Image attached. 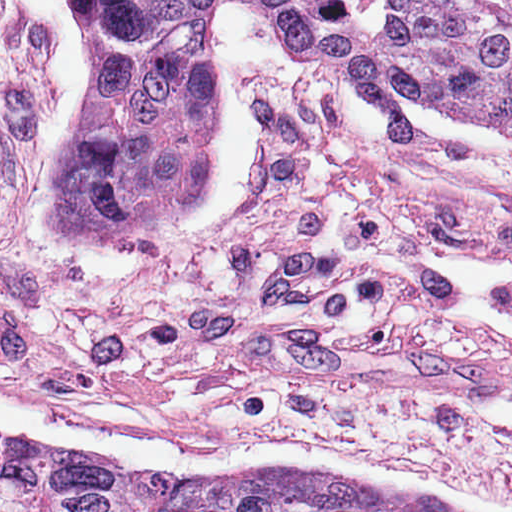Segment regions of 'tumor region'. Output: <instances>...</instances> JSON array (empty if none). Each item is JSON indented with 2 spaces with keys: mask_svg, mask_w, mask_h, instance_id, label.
Wrapping results in <instances>:
<instances>
[{
  "mask_svg": "<svg viewBox=\"0 0 512 512\" xmlns=\"http://www.w3.org/2000/svg\"><path fill=\"white\" fill-rule=\"evenodd\" d=\"M83 1L90 97L49 188L72 240L152 244L211 186L221 87L203 29L219 0ZM250 1L354 63L382 136L402 143L414 108L512 150V0ZM176 474L193 512H489L309 465Z\"/></svg>",
  "mask_w": 512,
  "mask_h": 512,
  "instance_id": "1",
  "label": "tumor region"
}]
</instances>
